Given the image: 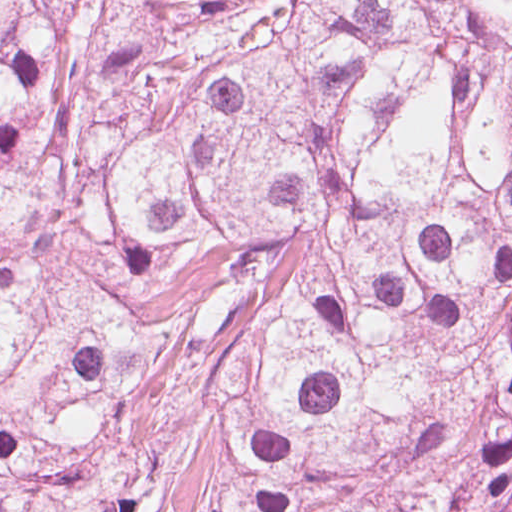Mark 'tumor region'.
<instances>
[{
	"label": "tumor region",
	"instance_id": "e687c5a6",
	"mask_svg": "<svg viewBox=\"0 0 512 512\" xmlns=\"http://www.w3.org/2000/svg\"><path fill=\"white\" fill-rule=\"evenodd\" d=\"M0 512H512V3L0 0Z\"/></svg>",
	"mask_w": 512,
	"mask_h": 512
}]
</instances>
